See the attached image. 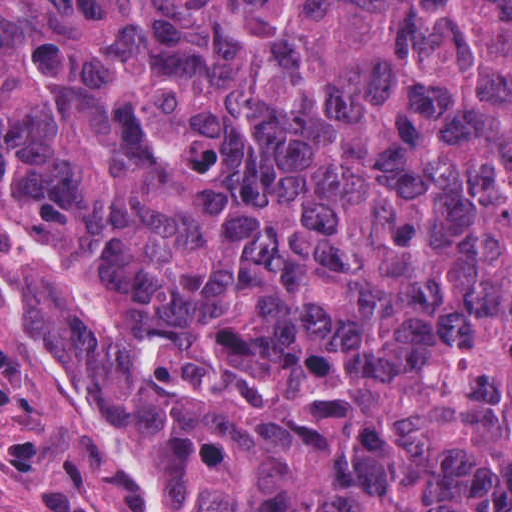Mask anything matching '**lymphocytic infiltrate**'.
<instances>
[{"mask_svg":"<svg viewBox=\"0 0 512 512\" xmlns=\"http://www.w3.org/2000/svg\"><path fill=\"white\" fill-rule=\"evenodd\" d=\"M25 512H112L79 480L42 471L26 485Z\"/></svg>","mask_w":512,"mask_h":512,"instance_id":"f902f5d3","label":"lymphocytic infiltrate"}]
</instances>
